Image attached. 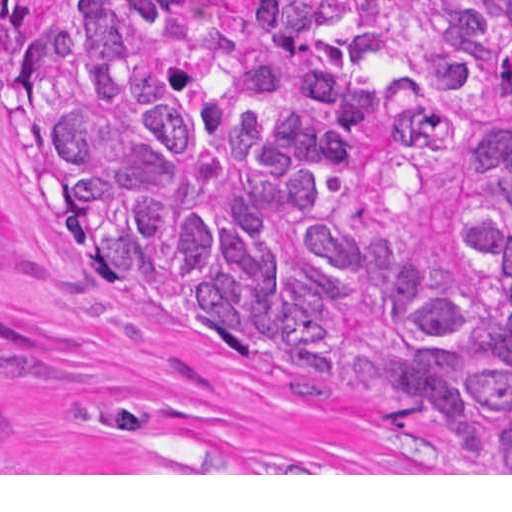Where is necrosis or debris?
<instances>
[{
  "label": "necrosis or debris",
  "mask_w": 512,
  "mask_h": 512,
  "mask_svg": "<svg viewBox=\"0 0 512 512\" xmlns=\"http://www.w3.org/2000/svg\"><path fill=\"white\" fill-rule=\"evenodd\" d=\"M179 1L193 49L217 68H240L251 55V33L264 11L297 0Z\"/></svg>",
  "instance_id": "necrosis-or-debris-1"
}]
</instances>
